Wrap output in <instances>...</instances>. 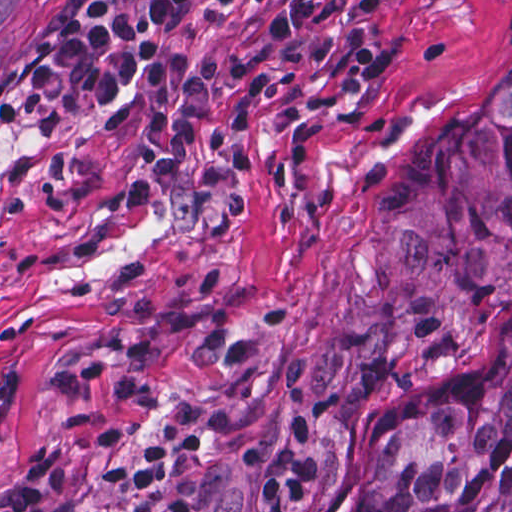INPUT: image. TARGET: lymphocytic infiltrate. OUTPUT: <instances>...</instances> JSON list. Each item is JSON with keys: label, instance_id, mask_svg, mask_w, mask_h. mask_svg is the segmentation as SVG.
I'll return each mask as SVG.
<instances>
[{"label": "lymphocytic infiltrate", "instance_id": "obj_1", "mask_svg": "<svg viewBox=\"0 0 512 512\" xmlns=\"http://www.w3.org/2000/svg\"><path fill=\"white\" fill-rule=\"evenodd\" d=\"M197 13L195 0H63L12 57L0 93L20 112L70 117L139 88V147L179 240L215 233L240 213L234 155L265 86H379L383 64L361 0H272L243 33L205 45L185 76L168 59ZM262 482L264 512H300L322 482L302 408L280 441L235 452ZM65 472L0 484V512H56Z\"/></svg>", "mask_w": 512, "mask_h": 512}]
</instances>
